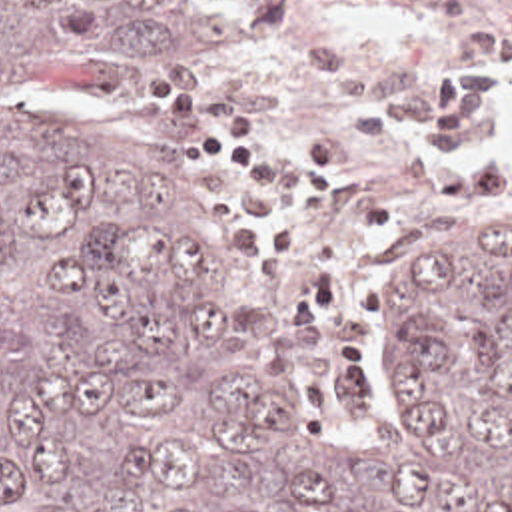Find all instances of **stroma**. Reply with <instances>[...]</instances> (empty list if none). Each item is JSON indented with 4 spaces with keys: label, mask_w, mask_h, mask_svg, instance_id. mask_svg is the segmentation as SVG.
<instances>
[{
    "label": "stroma",
    "mask_w": 512,
    "mask_h": 512,
    "mask_svg": "<svg viewBox=\"0 0 512 512\" xmlns=\"http://www.w3.org/2000/svg\"><path fill=\"white\" fill-rule=\"evenodd\" d=\"M208 2L226 20L232 36L210 56L93 100L59 102L35 92L21 94L69 114L143 166L180 204L204 210L226 238L236 265L252 279L266 301L276 335L290 353L316 409L328 421L330 441L342 453H364L382 417V365L392 327L400 315L406 279L400 252L430 238H512V208H486L466 216H426L380 232L376 261L386 289L370 325L378 401L372 417H336L322 405L316 385L300 361L278 293L242 254L236 224L220 214L210 186L190 182L180 172L182 126L172 116L147 108V94L150 86L182 72L218 76L262 98L282 126L294 130L312 146H334L348 140L350 122L300 58L302 42L350 46L366 52L380 76L394 88H432L458 60H494L474 48L470 40L474 24L494 10V0H332L288 34H262L250 16V0ZM498 62L512 68V56Z\"/></svg>",
    "instance_id": "35a3bbf8"
}]
</instances>
